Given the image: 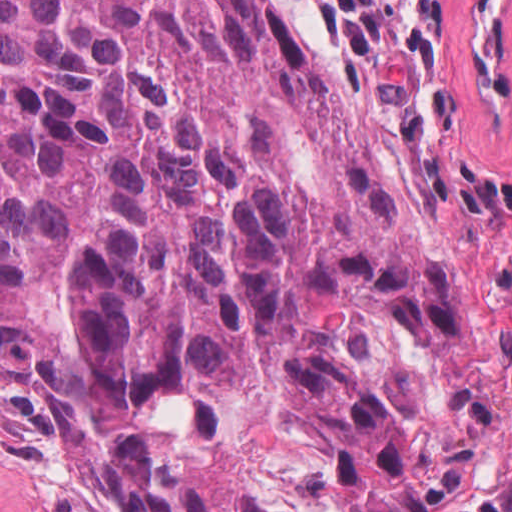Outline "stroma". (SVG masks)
Here are the masks:
<instances>
[{
	"mask_svg": "<svg viewBox=\"0 0 512 512\" xmlns=\"http://www.w3.org/2000/svg\"><path fill=\"white\" fill-rule=\"evenodd\" d=\"M267 1L325 40L381 173L481 300L495 469L463 512H493L512 495V0ZM0 512H99L63 422L21 381H0Z\"/></svg>",
	"mask_w": 512,
	"mask_h": 512,
	"instance_id": "1",
	"label": "stroma"
}]
</instances>
